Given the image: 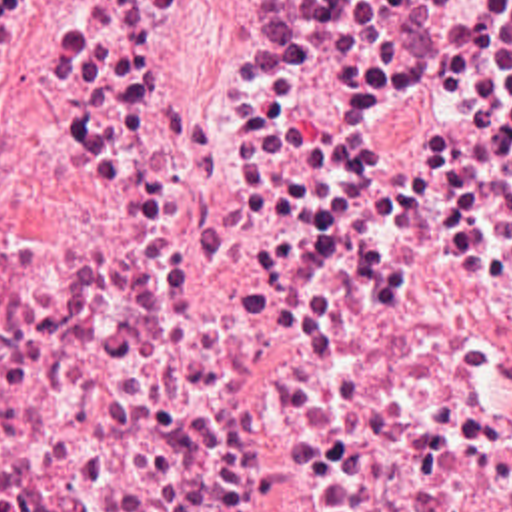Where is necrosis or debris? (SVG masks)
<instances>
[{
    "label": "necrosis or debris",
    "mask_w": 512,
    "mask_h": 512,
    "mask_svg": "<svg viewBox=\"0 0 512 512\" xmlns=\"http://www.w3.org/2000/svg\"><path fill=\"white\" fill-rule=\"evenodd\" d=\"M0 0V512H512V0Z\"/></svg>",
    "instance_id": "obj_1"
}]
</instances>
